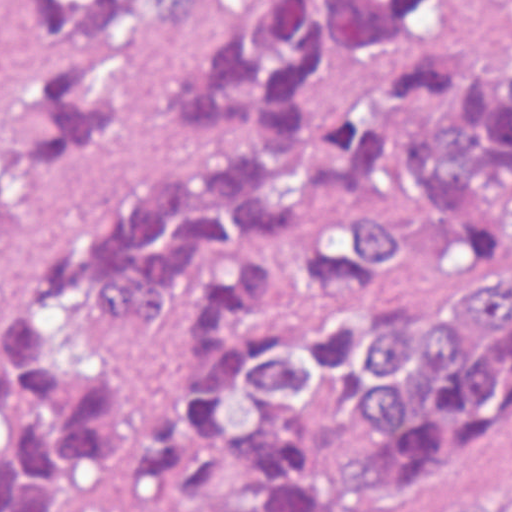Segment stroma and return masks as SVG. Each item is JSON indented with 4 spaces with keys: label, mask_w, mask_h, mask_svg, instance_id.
I'll return each mask as SVG.
<instances>
[{
    "label": "stroma",
    "mask_w": 512,
    "mask_h": 512,
    "mask_svg": "<svg viewBox=\"0 0 512 512\" xmlns=\"http://www.w3.org/2000/svg\"><path fill=\"white\" fill-rule=\"evenodd\" d=\"M190 302L140 357L126 379L116 470L99 512H245L235 502L237 488L251 478L256 462H238L222 474L204 502L190 505L157 496L143 483L134 465L138 432L171 396L188 358ZM431 308L401 314H423ZM338 317L315 297L273 276L270 302L239 308L236 323H319ZM466 493H486L498 512H512V415L498 434L446 465L348 486L342 502L332 512H457Z\"/></svg>",
    "instance_id": "35a3bbf8"
}]
</instances>
